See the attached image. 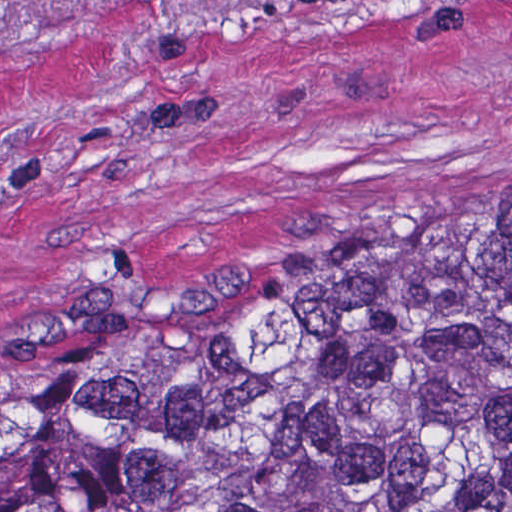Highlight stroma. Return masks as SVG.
Here are the masks:
<instances>
[{"mask_svg": "<svg viewBox=\"0 0 512 512\" xmlns=\"http://www.w3.org/2000/svg\"><path fill=\"white\" fill-rule=\"evenodd\" d=\"M512 191V0H0V392L87 275L167 295Z\"/></svg>", "mask_w": 512, "mask_h": 512, "instance_id": "stroma-1", "label": "stroma"}]
</instances>
